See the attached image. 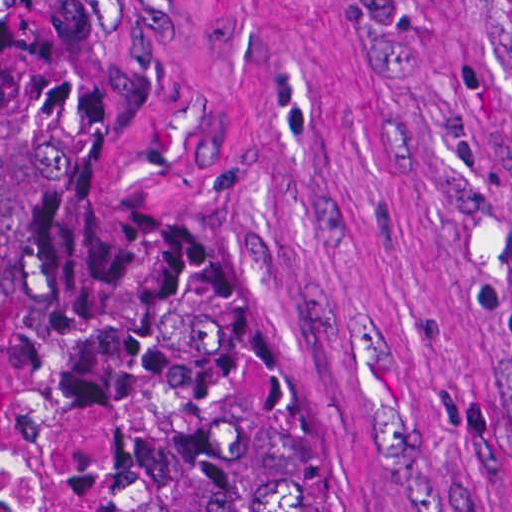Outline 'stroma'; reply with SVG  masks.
Listing matches in <instances>:
<instances>
[{
	"label": "stroma",
	"mask_w": 512,
	"mask_h": 512,
	"mask_svg": "<svg viewBox=\"0 0 512 512\" xmlns=\"http://www.w3.org/2000/svg\"><path fill=\"white\" fill-rule=\"evenodd\" d=\"M76 1L362 512H512V0ZM23 423L93 465L8 332Z\"/></svg>",
	"instance_id": "stroma-1"
}]
</instances>
